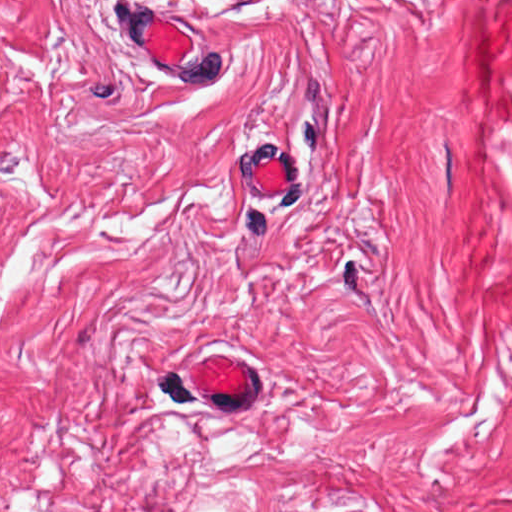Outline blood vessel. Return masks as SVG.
<instances>
[{"label":"blood vessel","instance_id":"obj_1","mask_svg":"<svg viewBox=\"0 0 512 512\" xmlns=\"http://www.w3.org/2000/svg\"><path fill=\"white\" fill-rule=\"evenodd\" d=\"M160 4L120 8V39L134 62L174 94H215L229 82V54L212 29ZM279 141L238 144L228 188L243 202L283 205L299 191V168ZM187 384L201 401L248 412L258 391V364L245 350L221 346L195 355ZM359 512V511H334Z\"/></svg>","mask_w":512,"mask_h":512}]
</instances>
